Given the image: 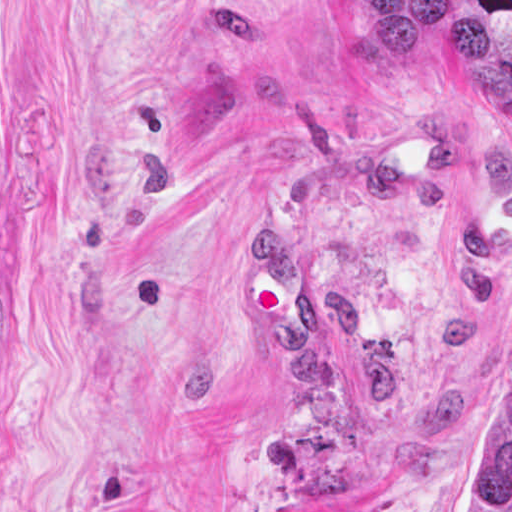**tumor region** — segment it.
I'll return each mask as SVG.
<instances>
[{
    "instance_id": "e687c5a6",
    "label": "tumor region",
    "mask_w": 512,
    "mask_h": 512,
    "mask_svg": "<svg viewBox=\"0 0 512 512\" xmlns=\"http://www.w3.org/2000/svg\"><path fill=\"white\" fill-rule=\"evenodd\" d=\"M466 512H512V364L466 463Z\"/></svg>"
}]
</instances>
